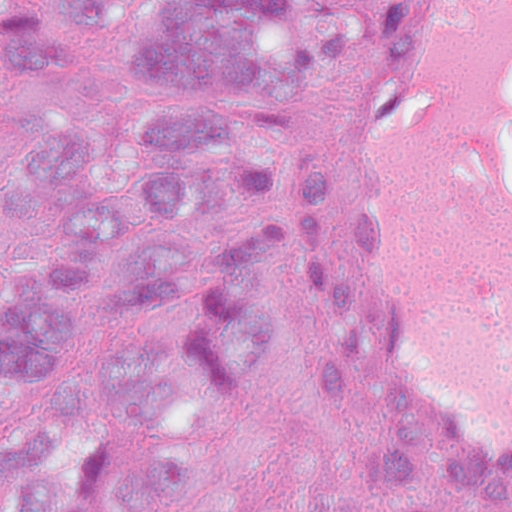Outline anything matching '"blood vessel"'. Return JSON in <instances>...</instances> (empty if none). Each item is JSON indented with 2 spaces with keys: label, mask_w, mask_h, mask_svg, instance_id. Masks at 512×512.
I'll use <instances>...</instances> for the list:
<instances>
[{
  "label": "blood vessel",
  "mask_w": 512,
  "mask_h": 512,
  "mask_svg": "<svg viewBox=\"0 0 512 512\" xmlns=\"http://www.w3.org/2000/svg\"><path fill=\"white\" fill-rule=\"evenodd\" d=\"M396 399L512 462V0H390L347 198Z\"/></svg>",
  "instance_id": "1"
}]
</instances>
